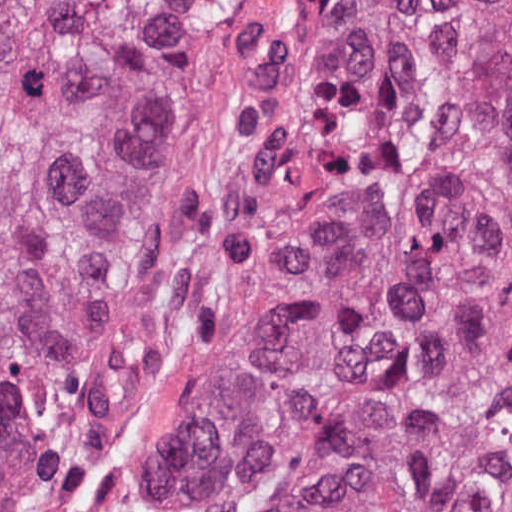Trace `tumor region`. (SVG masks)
<instances>
[{"instance_id":"obj_1","label":"tumor region","mask_w":512,"mask_h":512,"mask_svg":"<svg viewBox=\"0 0 512 512\" xmlns=\"http://www.w3.org/2000/svg\"><path fill=\"white\" fill-rule=\"evenodd\" d=\"M0 512H512V0H0Z\"/></svg>"}]
</instances>
